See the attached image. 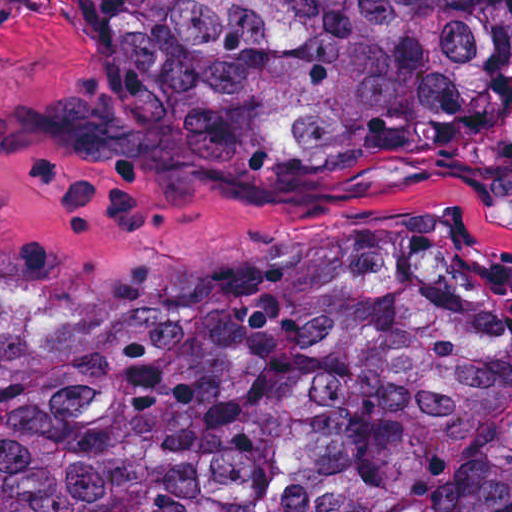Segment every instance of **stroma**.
<instances>
[{
	"instance_id": "obj_1",
	"label": "stroma",
	"mask_w": 512,
	"mask_h": 512,
	"mask_svg": "<svg viewBox=\"0 0 512 512\" xmlns=\"http://www.w3.org/2000/svg\"><path fill=\"white\" fill-rule=\"evenodd\" d=\"M512 155L332 173L217 152L148 0H0V297L138 315L272 252L456 226L512 294Z\"/></svg>"
}]
</instances>
